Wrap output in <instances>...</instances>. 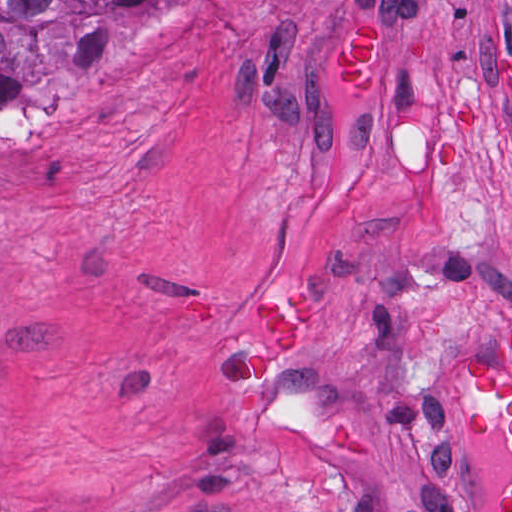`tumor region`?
<instances>
[{
	"mask_svg": "<svg viewBox=\"0 0 512 512\" xmlns=\"http://www.w3.org/2000/svg\"><path fill=\"white\" fill-rule=\"evenodd\" d=\"M148 0H0V109L13 110L42 83L86 85L102 69L118 27ZM383 20L372 9H353L337 36L334 85L345 95L383 92ZM315 303L292 287L256 297L249 332L253 379L240 391L229 422L242 432L257 418L263 386L278 371L312 321ZM457 389L479 407L457 429L484 440L502 431L512 465V330L504 336L502 368L470 361ZM329 444L345 460L366 462L358 428L324 426ZM497 512H512V491Z\"/></svg>",
	"mask_w": 512,
	"mask_h": 512,
	"instance_id": "obj_1",
	"label": "tumor region"
}]
</instances>
